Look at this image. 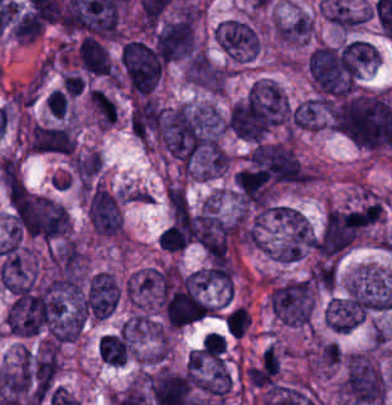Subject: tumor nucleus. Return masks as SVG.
<instances>
[{
	"label": "tumor nucleus",
	"mask_w": 392,
	"mask_h": 405,
	"mask_svg": "<svg viewBox=\"0 0 392 405\" xmlns=\"http://www.w3.org/2000/svg\"><path fill=\"white\" fill-rule=\"evenodd\" d=\"M342 352L332 340H318L312 349L308 365L313 373L331 374L341 364Z\"/></svg>",
	"instance_id": "feef74b5"
},
{
	"label": "tumor nucleus",
	"mask_w": 392,
	"mask_h": 405,
	"mask_svg": "<svg viewBox=\"0 0 392 405\" xmlns=\"http://www.w3.org/2000/svg\"><path fill=\"white\" fill-rule=\"evenodd\" d=\"M215 41L230 62L244 63L260 50V33L247 18H228L215 28Z\"/></svg>",
	"instance_id": "2cbd58db"
},
{
	"label": "tumor nucleus",
	"mask_w": 392,
	"mask_h": 405,
	"mask_svg": "<svg viewBox=\"0 0 392 405\" xmlns=\"http://www.w3.org/2000/svg\"><path fill=\"white\" fill-rule=\"evenodd\" d=\"M188 382L202 402L221 405L234 388L226 348L200 345L187 357Z\"/></svg>",
	"instance_id": "2f306a5c"
},
{
	"label": "tumor nucleus",
	"mask_w": 392,
	"mask_h": 405,
	"mask_svg": "<svg viewBox=\"0 0 392 405\" xmlns=\"http://www.w3.org/2000/svg\"><path fill=\"white\" fill-rule=\"evenodd\" d=\"M104 168L95 147H87L73 154L67 162V175L79 190H90Z\"/></svg>",
	"instance_id": "c2bd9aea"
},
{
	"label": "tumor nucleus",
	"mask_w": 392,
	"mask_h": 405,
	"mask_svg": "<svg viewBox=\"0 0 392 405\" xmlns=\"http://www.w3.org/2000/svg\"><path fill=\"white\" fill-rule=\"evenodd\" d=\"M226 349V339L216 331H209L201 341V350L210 358L220 359Z\"/></svg>",
	"instance_id": "268c6acd"
},
{
	"label": "tumor nucleus",
	"mask_w": 392,
	"mask_h": 405,
	"mask_svg": "<svg viewBox=\"0 0 392 405\" xmlns=\"http://www.w3.org/2000/svg\"><path fill=\"white\" fill-rule=\"evenodd\" d=\"M85 213L92 236L117 238L122 229L121 199L117 192L95 183L86 194Z\"/></svg>",
	"instance_id": "5ab6c2c4"
},
{
	"label": "tumor nucleus",
	"mask_w": 392,
	"mask_h": 405,
	"mask_svg": "<svg viewBox=\"0 0 392 405\" xmlns=\"http://www.w3.org/2000/svg\"><path fill=\"white\" fill-rule=\"evenodd\" d=\"M46 105L56 118L63 119L68 107V98L61 89H53Z\"/></svg>",
	"instance_id": "1edb0cf7"
},
{
	"label": "tumor nucleus",
	"mask_w": 392,
	"mask_h": 405,
	"mask_svg": "<svg viewBox=\"0 0 392 405\" xmlns=\"http://www.w3.org/2000/svg\"><path fill=\"white\" fill-rule=\"evenodd\" d=\"M164 290V272L157 264L135 269L124 280V297L134 311L154 312Z\"/></svg>",
	"instance_id": "3d1891a8"
},
{
	"label": "tumor nucleus",
	"mask_w": 392,
	"mask_h": 405,
	"mask_svg": "<svg viewBox=\"0 0 392 405\" xmlns=\"http://www.w3.org/2000/svg\"><path fill=\"white\" fill-rule=\"evenodd\" d=\"M182 75L187 84L218 94L226 85L227 70L205 52H191L182 62Z\"/></svg>",
	"instance_id": "8087334f"
},
{
	"label": "tumor nucleus",
	"mask_w": 392,
	"mask_h": 405,
	"mask_svg": "<svg viewBox=\"0 0 392 405\" xmlns=\"http://www.w3.org/2000/svg\"><path fill=\"white\" fill-rule=\"evenodd\" d=\"M314 290L308 277L270 280L267 302L277 321L307 326L312 318Z\"/></svg>",
	"instance_id": "8643909e"
},
{
	"label": "tumor nucleus",
	"mask_w": 392,
	"mask_h": 405,
	"mask_svg": "<svg viewBox=\"0 0 392 405\" xmlns=\"http://www.w3.org/2000/svg\"><path fill=\"white\" fill-rule=\"evenodd\" d=\"M224 323L227 332L242 337L251 324V316L244 306H236L227 313Z\"/></svg>",
	"instance_id": "f7901128"
},
{
	"label": "tumor nucleus",
	"mask_w": 392,
	"mask_h": 405,
	"mask_svg": "<svg viewBox=\"0 0 392 405\" xmlns=\"http://www.w3.org/2000/svg\"><path fill=\"white\" fill-rule=\"evenodd\" d=\"M308 277L317 289L332 291L337 281V264L327 258L316 259L311 264Z\"/></svg>",
	"instance_id": "3e47fb67"
},
{
	"label": "tumor nucleus",
	"mask_w": 392,
	"mask_h": 405,
	"mask_svg": "<svg viewBox=\"0 0 392 405\" xmlns=\"http://www.w3.org/2000/svg\"><path fill=\"white\" fill-rule=\"evenodd\" d=\"M77 151V136L71 124L31 122L28 153L71 156Z\"/></svg>",
	"instance_id": "2083b535"
}]
</instances>
